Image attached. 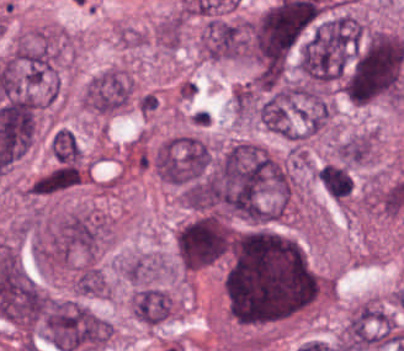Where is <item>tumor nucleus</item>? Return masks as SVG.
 Listing matches in <instances>:
<instances>
[{
    "label": "tumor nucleus",
    "mask_w": 404,
    "mask_h": 351,
    "mask_svg": "<svg viewBox=\"0 0 404 351\" xmlns=\"http://www.w3.org/2000/svg\"><path fill=\"white\" fill-rule=\"evenodd\" d=\"M39 328L62 351L102 347L108 339V319L69 297H49Z\"/></svg>",
    "instance_id": "obj_2"
},
{
    "label": "tumor nucleus",
    "mask_w": 404,
    "mask_h": 351,
    "mask_svg": "<svg viewBox=\"0 0 404 351\" xmlns=\"http://www.w3.org/2000/svg\"><path fill=\"white\" fill-rule=\"evenodd\" d=\"M174 303L170 292L163 287L138 285L128 299V308L139 322L156 325L168 319Z\"/></svg>",
    "instance_id": "obj_5"
},
{
    "label": "tumor nucleus",
    "mask_w": 404,
    "mask_h": 351,
    "mask_svg": "<svg viewBox=\"0 0 404 351\" xmlns=\"http://www.w3.org/2000/svg\"><path fill=\"white\" fill-rule=\"evenodd\" d=\"M331 153L336 161L346 165L366 163L373 156L372 137L358 132L333 143Z\"/></svg>",
    "instance_id": "obj_7"
},
{
    "label": "tumor nucleus",
    "mask_w": 404,
    "mask_h": 351,
    "mask_svg": "<svg viewBox=\"0 0 404 351\" xmlns=\"http://www.w3.org/2000/svg\"><path fill=\"white\" fill-rule=\"evenodd\" d=\"M174 240L183 269L195 271L225 255L232 232L226 218L204 212L181 223L175 230Z\"/></svg>",
    "instance_id": "obj_3"
},
{
    "label": "tumor nucleus",
    "mask_w": 404,
    "mask_h": 351,
    "mask_svg": "<svg viewBox=\"0 0 404 351\" xmlns=\"http://www.w3.org/2000/svg\"><path fill=\"white\" fill-rule=\"evenodd\" d=\"M315 175L333 200L345 201L352 191V177L346 165L325 162L315 170Z\"/></svg>",
    "instance_id": "obj_8"
},
{
    "label": "tumor nucleus",
    "mask_w": 404,
    "mask_h": 351,
    "mask_svg": "<svg viewBox=\"0 0 404 351\" xmlns=\"http://www.w3.org/2000/svg\"><path fill=\"white\" fill-rule=\"evenodd\" d=\"M85 176L82 164L55 163L28 184L29 195H49L72 186Z\"/></svg>",
    "instance_id": "obj_6"
},
{
    "label": "tumor nucleus",
    "mask_w": 404,
    "mask_h": 351,
    "mask_svg": "<svg viewBox=\"0 0 404 351\" xmlns=\"http://www.w3.org/2000/svg\"><path fill=\"white\" fill-rule=\"evenodd\" d=\"M48 149L58 164H77L82 152L69 128L56 127L48 138Z\"/></svg>",
    "instance_id": "obj_9"
},
{
    "label": "tumor nucleus",
    "mask_w": 404,
    "mask_h": 351,
    "mask_svg": "<svg viewBox=\"0 0 404 351\" xmlns=\"http://www.w3.org/2000/svg\"><path fill=\"white\" fill-rule=\"evenodd\" d=\"M198 51L207 59L244 60V17L209 16L199 32Z\"/></svg>",
    "instance_id": "obj_4"
},
{
    "label": "tumor nucleus",
    "mask_w": 404,
    "mask_h": 351,
    "mask_svg": "<svg viewBox=\"0 0 404 351\" xmlns=\"http://www.w3.org/2000/svg\"><path fill=\"white\" fill-rule=\"evenodd\" d=\"M404 71V43L393 33L362 32L341 75L344 95L358 104L391 99Z\"/></svg>",
    "instance_id": "obj_1"
}]
</instances>
